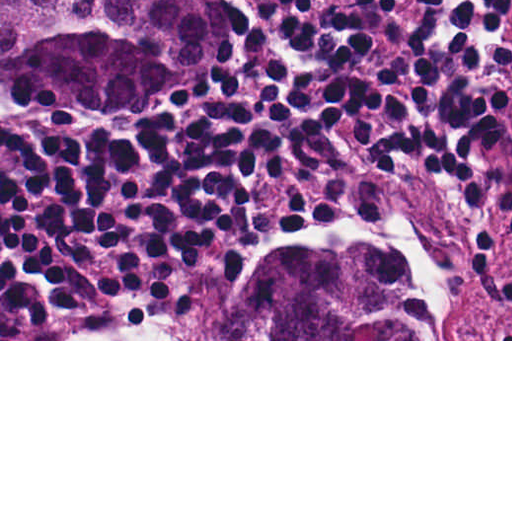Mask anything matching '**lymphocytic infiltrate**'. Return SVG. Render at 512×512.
Masks as SVG:
<instances>
[{
    "mask_svg": "<svg viewBox=\"0 0 512 512\" xmlns=\"http://www.w3.org/2000/svg\"><path fill=\"white\" fill-rule=\"evenodd\" d=\"M232 78L157 115L1 105V339L155 315L275 235L258 185L353 156L457 186L474 246L512 239V0H213ZM364 189L303 195L285 232ZM512 293V280L508 282Z\"/></svg>",
    "mask_w": 512,
    "mask_h": 512,
    "instance_id": "1",
    "label": "lymphocytic infiltrate"
}]
</instances>
